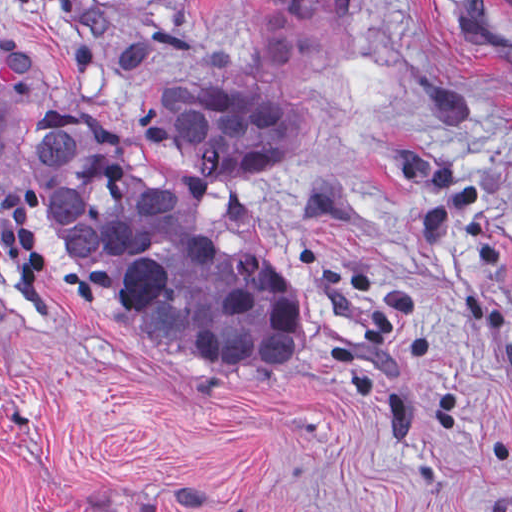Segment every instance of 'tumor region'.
<instances>
[{"mask_svg":"<svg viewBox=\"0 0 512 512\" xmlns=\"http://www.w3.org/2000/svg\"><path fill=\"white\" fill-rule=\"evenodd\" d=\"M276 1L326 53L347 0ZM71 22L108 70L146 81L151 104L132 122L94 123L1 32V157L9 118L35 103L28 180L59 251L96 298L167 343L259 368L294 359L302 316L242 184L287 140L301 101L210 77L220 35L79 11Z\"/></svg>","mask_w":512,"mask_h":512,"instance_id":"obj_1","label":"tumor region"}]
</instances>
